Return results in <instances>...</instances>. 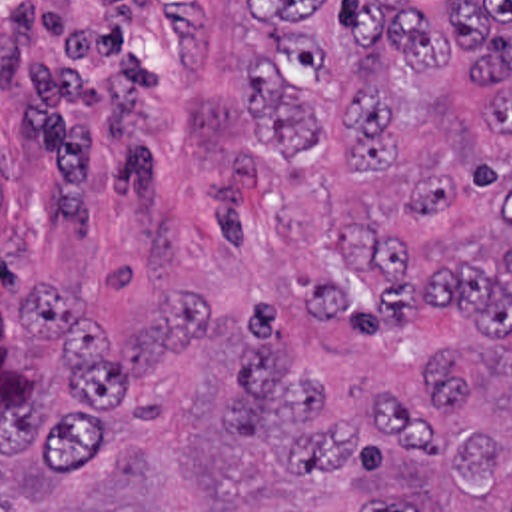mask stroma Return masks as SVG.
I'll list each match as a JSON object with an SVG mask.
<instances>
[{"instance_id": "1", "label": "stroma", "mask_w": 512, "mask_h": 512, "mask_svg": "<svg viewBox=\"0 0 512 512\" xmlns=\"http://www.w3.org/2000/svg\"><path fill=\"white\" fill-rule=\"evenodd\" d=\"M243 0H0V308L64 287L126 344L166 285L285 298L206 207L247 135Z\"/></svg>"}]
</instances>
